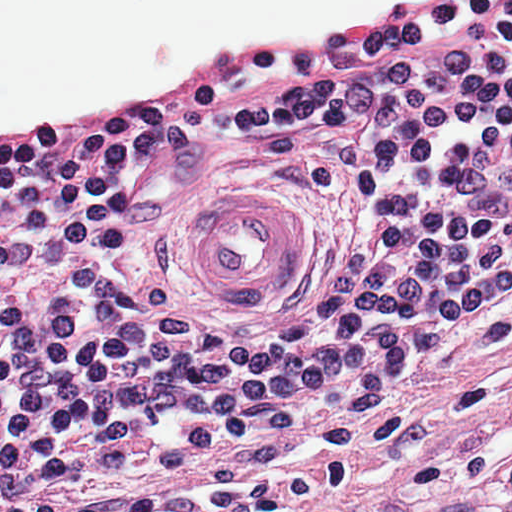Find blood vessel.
Masks as SVG:
<instances>
[{
    "instance_id": "8fb6f2fc",
    "label": "blood vessel",
    "mask_w": 512,
    "mask_h": 512,
    "mask_svg": "<svg viewBox=\"0 0 512 512\" xmlns=\"http://www.w3.org/2000/svg\"><path fill=\"white\" fill-rule=\"evenodd\" d=\"M196 264L217 298L253 306L299 268V225L267 185H223L197 198Z\"/></svg>"
}]
</instances>
